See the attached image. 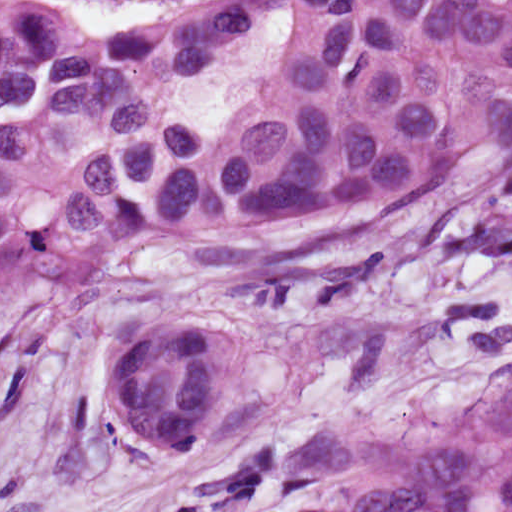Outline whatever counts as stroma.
<instances>
[{
  "mask_svg": "<svg viewBox=\"0 0 512 512\" xmlns=\"http://www.w3.org/2000/svg\"><path fill=\"white\" fill-rule=\"evenodd\" d=\"M106 23L147 0H66ZM381 272L256 306L167 236L120 268L0 282V512H190L512 366V150L356 220ZM141 320L224 341V401L153 458L111 413V346Z\"/></svg>",
  "mask_w": 512,
  "mask_h": 512,
  "instance_id": "1",
  "label": "stroma"
}]
</instances>
